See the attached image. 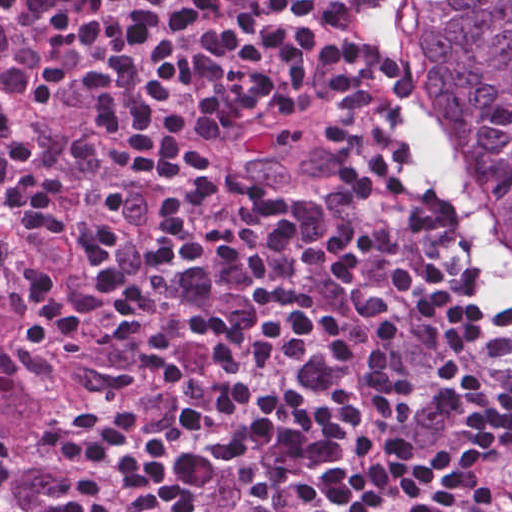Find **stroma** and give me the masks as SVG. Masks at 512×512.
Returning a JSON list of instances; mask_svg holds the SVG:
<instances>
[{
	"label": "stroma",
	"mask_w": 512,
	"mask_h": 512,
	"mask_svg": "<svg viewBox=\"0 0 512 512\" xmlns=\"http://www.w3.org/2000/svg\"><path fill=\"white\" fill-rule=\"evenodd\" d=\"M379 4L383 10V14H384L387 22H388L386 0H379ZM425 141H426L427 149L430 153V156H431L434 166L436 168L437 174H438L447 194L449 195V197H450V199L460 217V220L462 222V225H463L465 231L477 242V244H478L479 248L481 249L482 253L484 254L486 260L488 261V263L490 264L493 271L495 272V274L498 277L500 291L506 297V300L508 301V303L512 306V288L507 283L505 277L499 271V269L497 268V266L494 263V261L492 260V258L486 252L483 242H482V239H481V236H480L479 232L477 231V229L475 228V226L473 225V223H472V221H471V219L461 201V198L457 192V189H456L453 181L451 180V178L449 177L447 172L443 169V167L440 165L436 155L430 148L426 138H425Z\"/></svg>",
	"instance_id": "obj_1"
}]
</instances>
